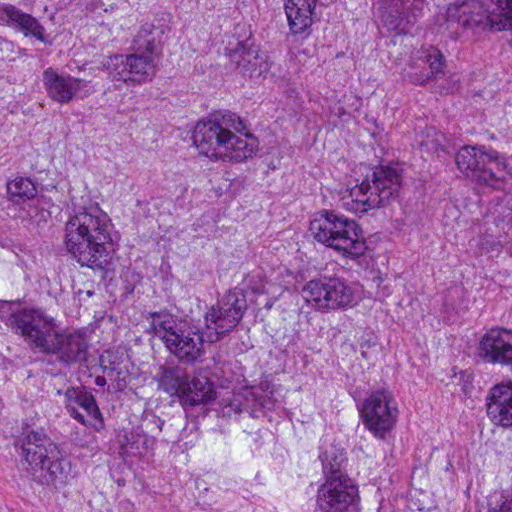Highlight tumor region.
<instances>
[{
  "mask_svg": "<svg viewBox=\"0 0 512 512\" xmlns=\"http://www.w3.org/2000/svg\"><path fill=\"white\" fill-rule=\"evenodd\" d=\"M0 512H512V0H0Z\"/></svg>",
  "mask_w": 512,
  "mask_h": 512,
  "instance_id": "1",
  "label": "tumor region"
}]
</instances>
